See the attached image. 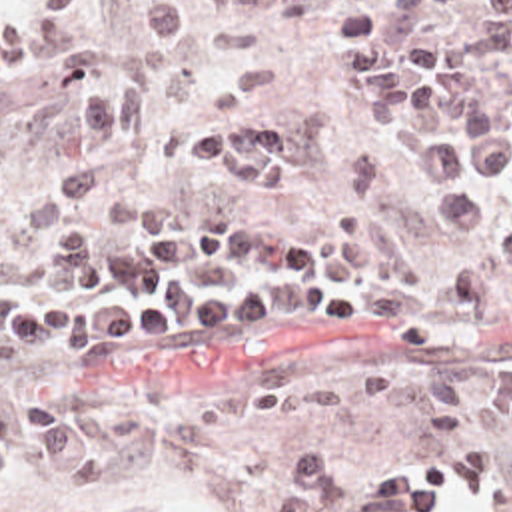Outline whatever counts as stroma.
Listing matches in <instances>:
<instances>
[{"instance_id":"35a3bbf8","label":"stroma","mask_w":512,"mask_h":512,"mask_svg":"<svg viewBox=\"0 0 512 512\" xmlns=\"http://www.w3.org/2000/svg\"><path fill=\"white\" fill-rule=\"evenodd\" d=\"M136 10L138 0H0V240L20 254L6 278L44 286L62 232L94 230L108 206L142 194L210 192L230 212L293 224L317 242L329 222L359 216L439 276L512 244V186L483 192L487 220L469 234L435 218L401 152L407 130L433 122L407 110L391 128L349 118L335 20L343 10L393 18V0H238L188 36L130 110L104 192L54 198L46 182L80 150L88 88L122 74ZM451 32L511 100L512 26L463 14ZM238 122H295L311 140V170L283 188H242L180 160V142ZM118 356L102 370L0 364V386L84 402L82 426L110 456V488L56 492L24 454L0 482V512H269L293 486L285 464L315 450H331L341 484L369 488L487 442L512 480V300L409 342L351 324L206 320ZM451 512L495 510L459 498Z\"/></svg>"}]
</instances>
